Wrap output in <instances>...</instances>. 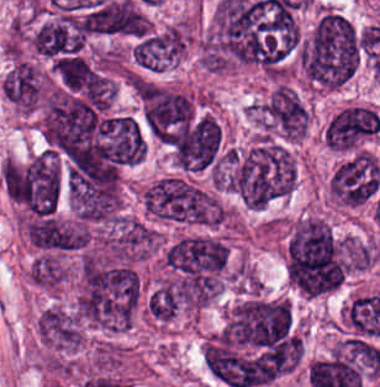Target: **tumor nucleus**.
Returning <instances> with one entry per match:
<instances>
[{
	"label": "tumor nucleus",
	"instance_id": "6",
	"mask_svg": "<svg viewBox=\"0 0 380 387\" xmlns=\"http://www.w3.org/2000/svg\"><path fill=\"white\" fill-rule=\"evenodd\" d=\"M379 130V114L373 107L348 104L329 119L324 141L331 150L353 152L374 139Z\"/></svg>",
	"mask_w": 380,
	"mask_h": 387
},
{
	"label": "tumor nucleus",
	"instance_id": "3",
	"mask_svg": "<svg viewBox=\"0 0 380 387\" xmlns=\"http://www.w3.org/2000/svg\"><path fill=\"white\" fill-rule=\"evenodd\" d=\"M176 166L182 171H201L220 159L222 125L203 112L172 128L165 137Z\"/></svg>",
	"mask_w": 380,
	"mask_h": 387
},
{
	"label": "tumor nucleus",
	"instance_id": "2",
	"mask_svg": "<svg viewBox=\"0 0 380 387\" xmlns=\"http://www.w3.org/2000/svg\"><path fill=\"white\" fill-rule=\"evenodd\" d=\"M148 216L163 223L217 225L216 197L183 177H163L141 193Z\"/></svg>",
	"mask_w": 380,
	"mask_h": 387
},
{
	"label": "tumor nucleus",
	"instance_id": "7",
	"mask_svg": "<svg viewBox=\"0 0 380 387\" xmlns=\"http://www.w3.org/2000/svg\"><path fill=\"white\" fill-rule=\"evenodd\" d=\"M187 42V23L148 30L131 46V60L150 71H164L178 64Z\"/></svg>",
	"mask_w": 380,
	"mask_h": 387
},
{
	"label": "tumor nucleus",
	"instance_id": "1",
	"mask_svg": "<svg viewBox=\"0 0 380 387\" xmlns=\"http://www.w3.org/2000/svg\"><path fill=\"white\" fill-rule=\"evenodd\" d=\"M359 40L356 29L340 12L325 9L299 42V67L316 89L338 87L358 68Z\"/></svg>",
	"mask_w": 380,
	"mask_h": 387
},
{
	"label": "tumor nucleus",
	"instance_id": "8",
	"mask_svg": "<svg viewBox=\"0 0 380 387\" xmlns=\"http://www.w3.org/2000/svg\"><path fill=\"white\" fill-rule=\"evenodd\" d=\"M36 327L44 341L62 351L73 352L82 343L77 317L61 308H47L39 315Z\"/></svg>",
	"mask_w": 380,
	"mask_h": 387
},
{
	"label": "tumor nucleus",
	"instance_id": "5",
	"mask_svg": "<svg viewBox=\"0 0 380 387\" xmlns=\"http://www.w3.org/2000/svg\"><path fill=\"white\" fill-rule=\"evenodd\" d=\"M380 162L365 149H358L340 164L330 178L331 199L343 208H358L377 195Z\"/></svg>",
	"mask_w": 380,
	"mask_h": 387
},
{
	"label": "tumor nucleus",
	"instance_id": "9",
	"mask_svg": "<svg viewBox=\"0 0 380 387\" xmlns=\"http://www.w3.org/2000/svg\"><path fill=\"white\" fill-rule=\"evenodd\" d=\"M28 275L36 287L53 288L67 277L66 268L58 255L42 252L28 268Z\"/></svg>",
	"mask_w": 380,
	"mask_h": 387
},
{
	"label": "tumor nucleus",
	"instance_id": "4",
	"mask_svg": "<svg viewBox=\"0 0 380 387\" xmlns=\"http://www.w3.org/2000/svg\"><path fill=\"white\" fill-rule=\"evenodd\" d=\"M137 98L152 139L170 145L194 113L191 97L162 86L139 82Z\"/></svg>",
	"mask_w": 380,
	"mask_h": 387
}]
</instances>
